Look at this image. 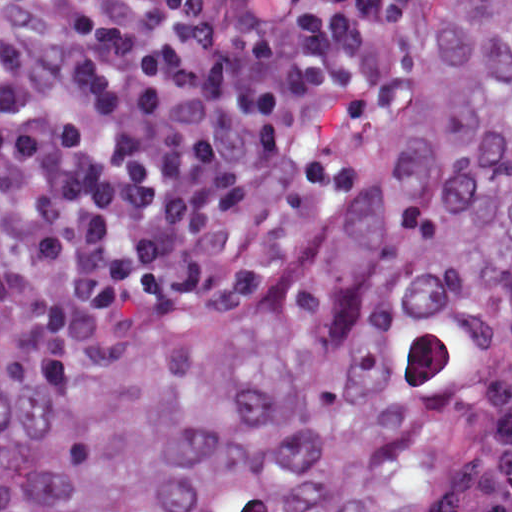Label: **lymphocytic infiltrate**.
<instances>
[{
	"label": "lymphocytic infiltrate",
	"instance_id": "1",
	"mask_svg": "<svg viewBox=\"0 0 512 512\" xmlns=\"http://www.w3.org/2000/svg\"><path fill=\"white\" fill-rule=\"evenodd\" d=\"M435 0H1V282L291 264L393 141Z\"/></svg>",
	"mask_w": 512,
	"mask_h": 512
}]
</instances>
